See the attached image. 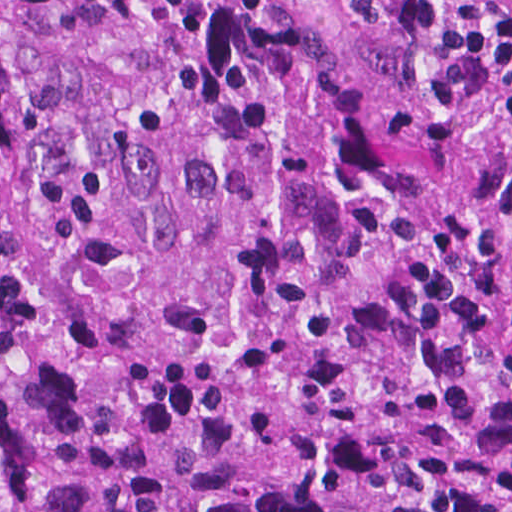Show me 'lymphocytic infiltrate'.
<instances>
[{"label": "lymphocytic infiltrate", "mask_w": 512, "mask_h": 512, "mask_svg": "<svg viewBox=\"0 0 512 512\" xmlns=\"http://www.w3.org/2000/svg\"><path fill=\"white\" fill-rule=\"evenodd\" d=\"M369 23L408 32L435 28L442 6L451 24L441 97L457 127L497 167L512 171V0H354Z\"/></svg>", "instance_id": "obj_1"}]
</instances>
